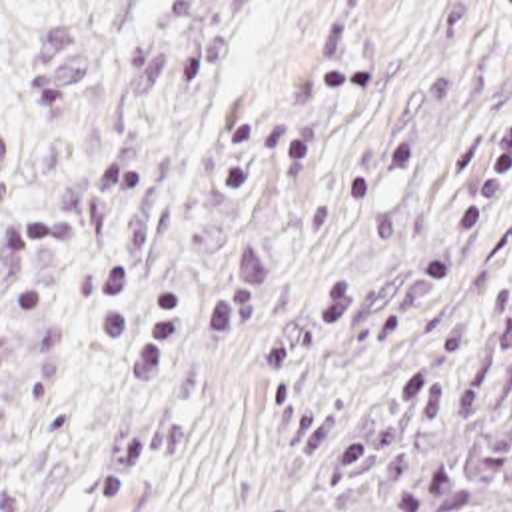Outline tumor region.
I'll return each mask as SVG.
<instances>
[{"label": "tumor region", "mask_w": 512, "mask_h": 512, "mask_svg": "<svg viewBox=\"0 0 512 512\" xmlns=\"http://www.w3.org/2000/svg\"><path fill=\"white\" fill-rule=\"evenodd\" d=\"M292 512H512V198L353 392Z\"/></svg>", "instance_id": "1"}]
</instances>
